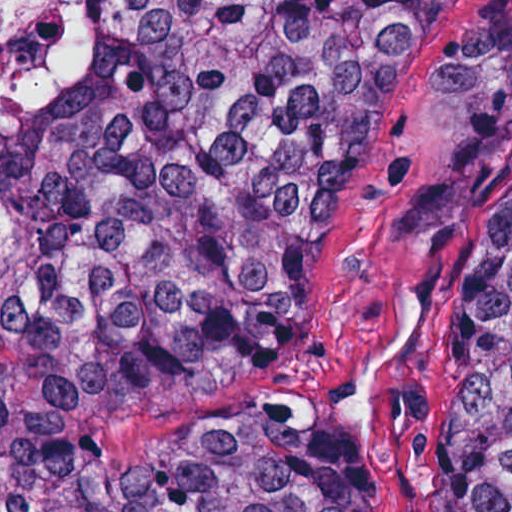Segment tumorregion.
Returning <instances> with one entry per match:
<instances>
[{"label": "tumor region", "instance_id": "e687c5a6", "mask_svg": "<svg viewBox=\"0 0 512 512\" xmlns=\"http://www.w3.org/2000/svg\"><path fill=\"white\" fill-rule=\"evenodd\" d=\"M446 0H128L65 98H0V512H359L275 426L143 470L115 422L244 383V288L355 188ZM445 512H512V170L471 243Z\"/></svg>", "mask_w": 512, "mask_h": 512}]
</instances>
